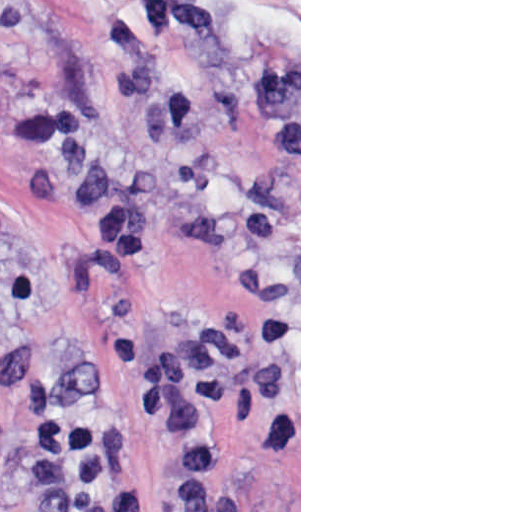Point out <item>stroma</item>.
I'll return each mask as SVG.
<instances>
[{
	"instance_id": "35a3bbf8",
	"label": "stroma",
	"mask_w": 512,
	"mask_h": 512,
	"mask_svg": "<svg viewBox=\"0 0 512 512\" xmlns=\"http://www.w3.org/2000/svg\"><path fill=\"white\" fill-rule=\"evenodd\" d=\"M209 327L191 474L135 369ZM38 381L119 423L110 512H301V0H0V512H40Z\"/></svg>"
}]
</instances>
